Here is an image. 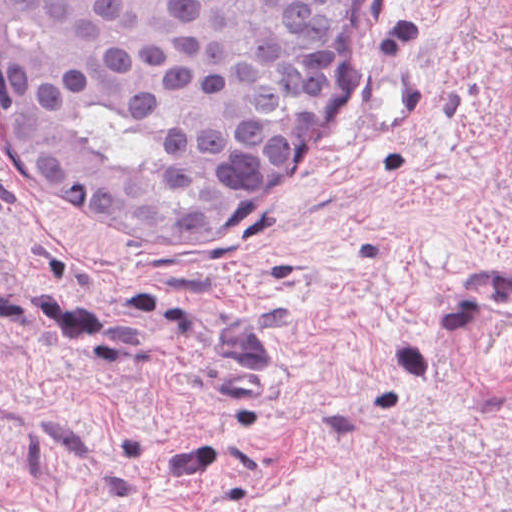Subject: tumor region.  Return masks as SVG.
<instances>
[{
    "label": "tumor region",
    "mask_w": 512,
    "mask_h": 512,
    "mask_svg": "<svg viewBox=\"0 0 512 512\" xmlns=\"http://www.w3.org/2000/svg\"><path fill=\"white\" fill-rule=\"evenodd\" d=\"M356 0H0L19 159L125 229H194L331 84Z\"/></svg>",
    "instance_id": "1"
}]
</instances>
